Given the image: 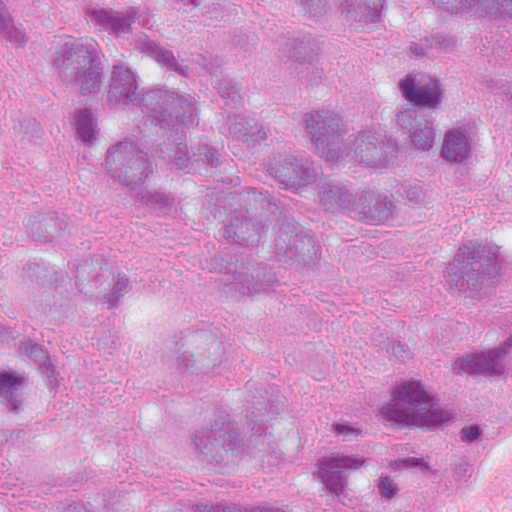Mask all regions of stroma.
Masks as SVG:
<instances>
[{
  "label": "stroma",
  "mask_w": 512,
  "mask_h": 512,
  "mask_svg": "<svg viewBox=\"0 0 512 512\" xmlns=\"http://www.w3.org/2000/svg\"><path fill=\"white\" fill-rule=\"evenodd\" d=\"M87 0H33L20 33L0 44V206L26 182L62 177L128 262L137 305L154 333L176 339L215 312L223 293L203 262L140 192L66 133L52 106L49 42ZM104 301L85 317L82 391L62 421L68 457L107 465L138 489L136 512L158 508L175 475L160 406L127 347L104 357ZM283 379L324 387L427 363L455 367L441 333L425 261L395 241L357 243L330 281L286 299L274 317ZM404 462L382 477L360 512H390Z\"/></svg>",
  "instance_id": "stroma-1"
}]
</instances>
